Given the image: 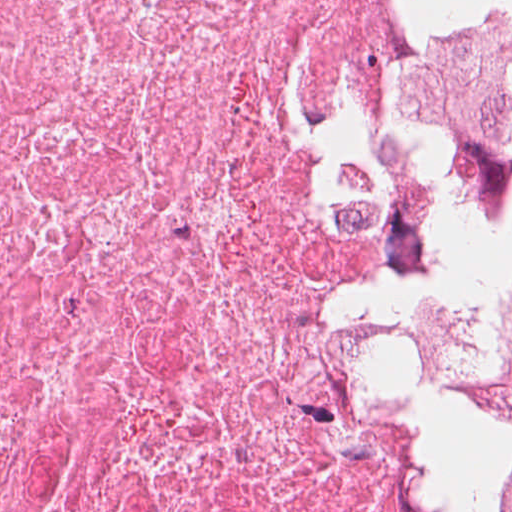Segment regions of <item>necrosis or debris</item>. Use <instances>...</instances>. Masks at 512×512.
Segmentation results:
<instances>
[{
	"label": "necrosis or debris",
	"mask_w": 512,
	"mask_h": 512,
	"mask_svg": "<svg viewBox=\"0 0 512 512\" xmlns=\"http://www.w3.org/2000/svg\"><path fill=\"white\" fill-rule=\"evenodd\" d=\"M512 208V0H0V512H419Z\"/></svg>",
	"instance_id": "4bbe7bcc"
}]
</instances>
